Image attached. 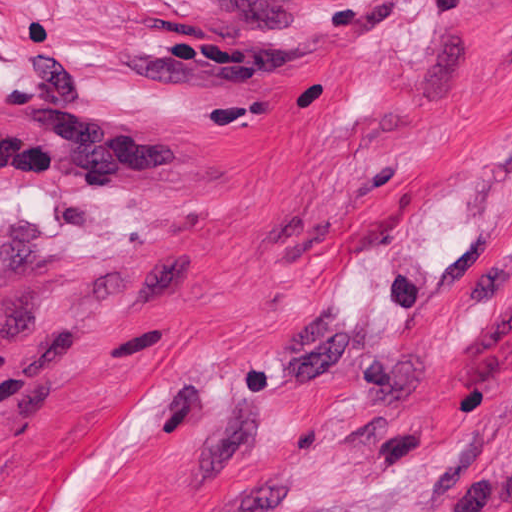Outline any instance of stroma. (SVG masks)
Returning a JSON list of instances; mask_svg holds the SVG:
<instances>
[{
  "instance_id": "1",
  "label": "stroma",
  "mask_w": 512,
  "mask_h": 512,
  "mask_svg": "<svg viewBox=\"0 0 512 512\" xmlns=\"http://www.w3.org/2000/svg\"><path fill=\"white\" fill-rule=\"evenodd\" d=\"M188 133L0 169V512H512V0H0Z\"/></svg>"
}]
</instances>
